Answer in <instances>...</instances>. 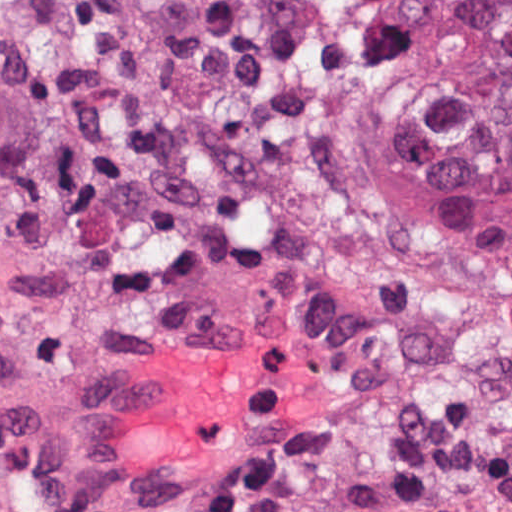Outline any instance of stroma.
<instances>
[{
    "label": "stroma",
    "instance_id": "1",
    "mask_svg": "<svg viewBox=\"0 0 512 512\" xmlns=\"http://www.w3.org/2000/svg\"><path fill=\"white\" fill-rule=\"evenodd\" d=\"M375 150L411 223L432 247L499 274L512 272V258L419 183L399 144L394 79L388 88L386 134ZM268 326L273 327L259 332L283 340L301 366L179 510L241 512V502L250 488L287 463L299 442L316 433L329 414L335 392L333 367L312 336L272 313L215 315L138 351L0 382V419L76 388L171 341L195 334Z\"/></svg>",
    "mask_w": 512,
    "mask_h": 512
}]
</instances>
